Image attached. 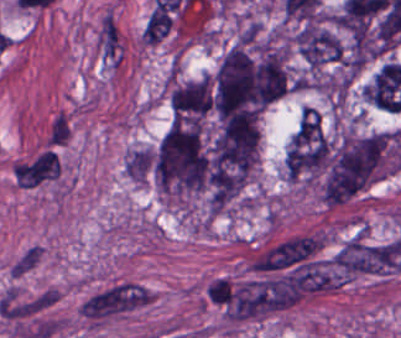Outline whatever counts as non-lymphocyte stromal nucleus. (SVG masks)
Masks as SVG:
<instances>
[{"mask_svg":"<svg viewBox=\"0 0 401 338\" xmlns=\"http://www.w3.org/2000/svg\"><path fill=\"white\" fill-rule=\"evenodd\" d=\"M150 291L134 281L122 280L88 294L78 311L88 322H101L140 306Z\"/></svg>","mask_w":401,"mask_h":338,"instance_id":"dd21d789","label":"non-lymphocyte stromal nucleus"},{"mask_svg":"<svg viewBox=\"0 0 401 338\" xmlns=\"http://www.w3.org/2000/svg\"><path fill=\"white\" fill-rule=\"evenodd\" d=\"M179 4L176 1H154L147 13L143 25L144 42H159L173 29Z\"/></svg>","mask_w":401,"mask_h":338,"instance_id":"a72fc3eb","label":"non-lymphocyte stromal nucleus"},{"mask_svg":"<svg viewBox=\"0 0 401 338\" xmlns=\"http://www.w3.org/2000/svg\"><path fill=\"white\" fill-rule=\"evenodd\" d=\"M61 167L39 152L20 161L14 178L21 187H32L54 177Z\"/></svg>","mask_w":401,"mask_h":338,"instance_id":"3746e769","label":"non-lymphocyte stromal nucleus"},{"mask_svg":"<svg viewBox=\"0 0 401 338\" xmlns=\"http://www.w3.org/2000/svg\"><path fill=\"white\" fill-rule=\"evenodd\" d=\"M71 128L65 115H56L50 125L49 140L53 144L65 142L69 138Z\"/></svg>","mask_w":401,"mask_h":338,"instance_id":"fc2b8d12","label":"non-lymphocyte stromal nucleus"}]
</instances>
